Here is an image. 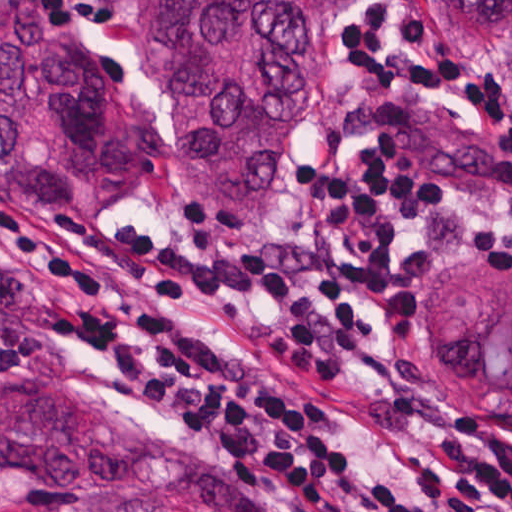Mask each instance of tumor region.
<instances>
[{
	"label": "tumor region",
	"instance_id": "tumor-region-1",
	"mask_svg": "<svg viewBox=\"0 0 512 512\" xmlns=\"http://www.w3.org/2000/svg\"><path fill=\"white\" fill-rule=\"evenodd\" d=\"M362 1L151 0L145 62L172 81L165 133L119 107L38 0H0V181L27 211L86 209L169 149L210 215L254 226L287 188L329 33ZM433 5L468 47L512 52V0ZM419 340L467 410H512V274L500 263L440 266L419 293ZM0 481L28 489L8 512H308L83 387L29 391L0 412Z\"/></svg>",
	"mask_w": 512,
	"mask_h": 512
}]
</instances>
